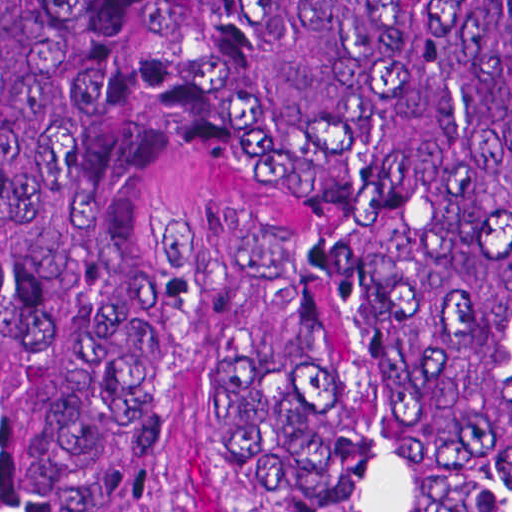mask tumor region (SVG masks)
I'll use <instances>...</instances> for the list:
<instances>
[{
    "mask_svg": "<svg viewBox=\"0 0 512 512\" xmlns=\"http://www.w3.org/2000/svg\"><path fill=\"white\" fill-rule=\"evenodd\" d=\"M512 509V0H0V512Z\"/></svg>",
    "mask_w": 512,
    "mask_h": 512,
    "instance_id": "tumor-region-1",
    "label": "tumor region"
}]
</instances>
